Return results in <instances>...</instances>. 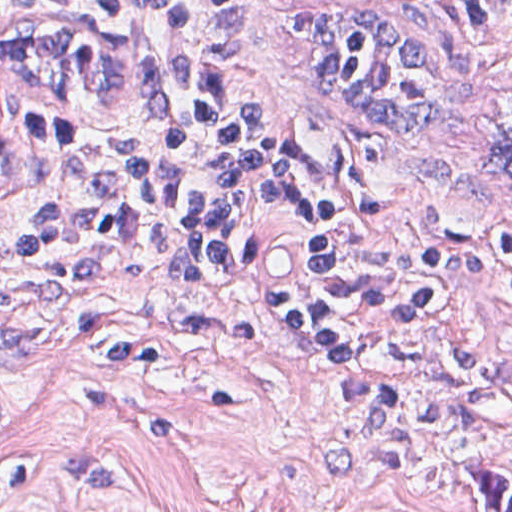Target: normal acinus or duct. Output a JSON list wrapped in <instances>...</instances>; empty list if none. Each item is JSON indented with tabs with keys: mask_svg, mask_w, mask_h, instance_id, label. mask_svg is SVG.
<instances>
[{
	"mask_svg": "<svg viewBox=\"0 0 512 512\" xmlns=\"http://www.w3.org/2000/svg\"><path fill=\"white\" fill-rule=\"evenodd\" d=\"M10 86L74 105L122 107L146 93V57L134 37L78 22H1L0 90ZM500 162L512 182V119Z\"/></svg>",
	"mask_w": 512,
	"mask_h": 512,
	"instance_id": "30e58d81",
	"label": "normal acinus or duct"
}]
</instances>
